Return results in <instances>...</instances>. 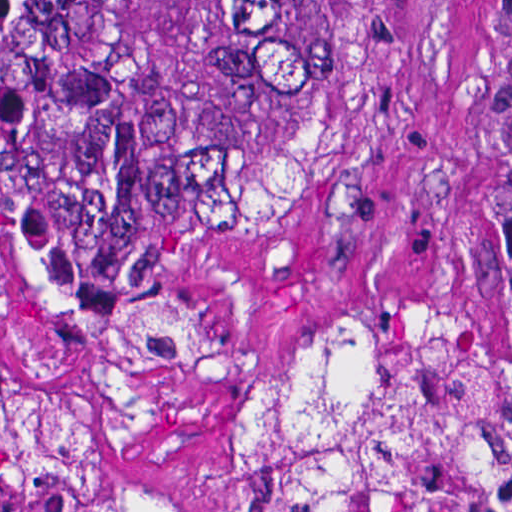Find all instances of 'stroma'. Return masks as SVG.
Instances as JSON below:
<instances>
[{
  "instance_id": "stroma-1",
  "label": "stroma",
  "mask_w": 512,
  "mask_h": 512,
  "mask_svg": "<svg viewBox=\"0 0 512 512\" xmlns=\"http://www.w3.org/2000/svg\"><path fill=\"white\" fill-rule=\"evenodd\" d=\"M380 1L371 87L302 203L254 243L160 275L212 319L224 362L99 436L95 479L112 494L160 512H257L245 378L277 333L332 298H435L512 342V0ZM0 364L29 392L82 377L79 347L18 288L1 239Z\"/></svg>"
}]
</instances>
